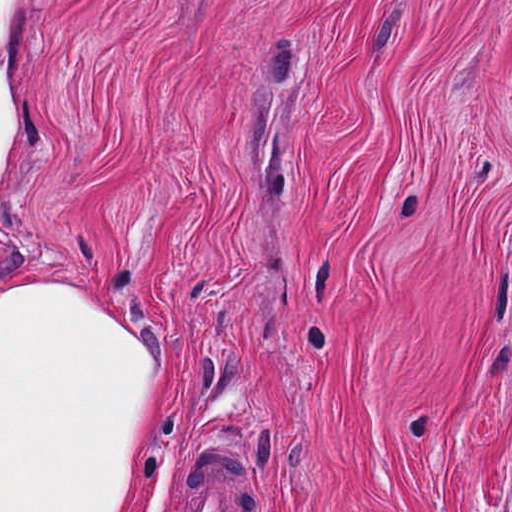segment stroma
<instances>
[{"instance_id":"stroma-1","label":"stroma","mask_w":512,"mask_h":512,"mask_svg":"<svg viewBox=\"0 0 512 512\" xmlns=\"http://www.w3.org/2000/svg\"><path fill=\"white\" fill-rule=\"evenodd\" d=\"M0 283L157 376L124 512H512V0H31ZM218 441V442H217Z\"/></svg>"}]
</instances>
